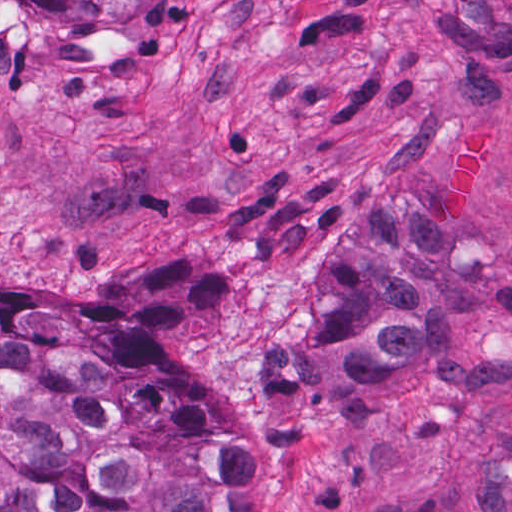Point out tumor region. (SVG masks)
I'll return each instance as SVG.
<instances>
[{
  "instance_id": "obj_1",
  "label": "tumor region",
  "mask_w": 512,
  "mask_h": 512,
  "mask_svg": "<svg viewBox=\"0 0 512 512\" xmlns=\"http://www.w3.org/2000/svg\"><path fill=\"white\" fill-rule=\"evenodd\" d=\"M63 48L117 15L174 30L179 0H23ZM228 282L201 264H148L116 299L0 289V512H256L246 446L205 411L194 378L133 339L211 311ZM505 311L420 209L355 195L315 329L245 392L243 426H279L336 397L402 400L423 369L495 349Z\"/></svg>"
}]
</instances>
